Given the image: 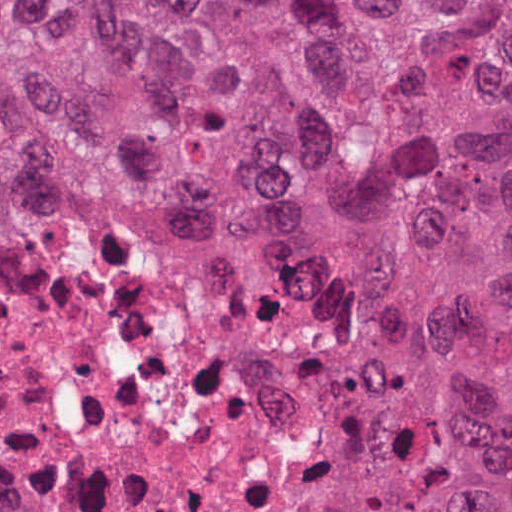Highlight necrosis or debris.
Returning <instances> with one entry per match:
<instances>
[{"instance_id":"1","label":"necrosis or debris","mask_w":512,"mask_h":512,"mask_svg":"<svg viewBox=\"0 0 512 512\" xmlns=\"http://www.w3.org/2000/svg\"><path fill=\"white\" fill-rule=\"evenodd\" d=\"M351 257L115 229L0 266V512H336Z\"/></svg>"}]
</instances>
